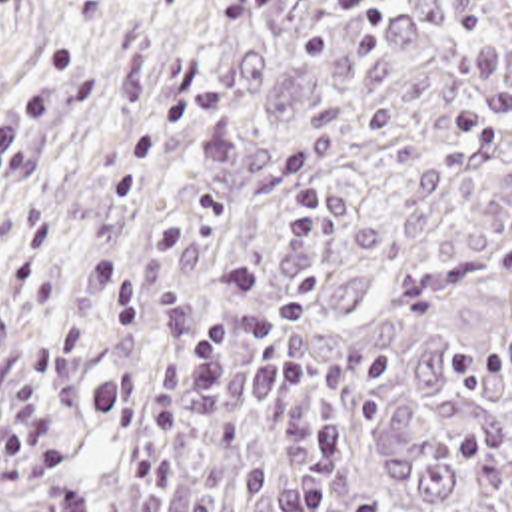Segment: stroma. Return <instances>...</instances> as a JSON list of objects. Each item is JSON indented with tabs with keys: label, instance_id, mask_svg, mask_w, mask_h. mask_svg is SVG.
I'll list each match as a JSON object with an SVG mask.
<instances>
[{
	"label": "stroma",
	"instance_id": "stroma-1",
	"mask_svg": "<svg viewBox=\"0 0 512 512\" xmlns=\"http://www.w3.org/2000/svg\"><path fill=\"white\" fill-rule=\"evenodd\" d=\"M151 0H0V198L107 70Z\"/></svg>",
	"mask_w": 512,
	"mask_h": 512
}]
</instances>
